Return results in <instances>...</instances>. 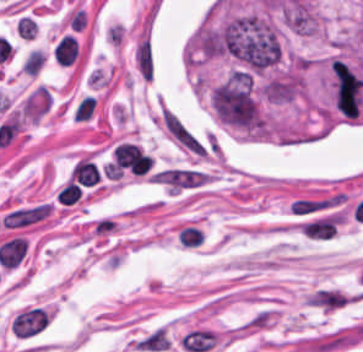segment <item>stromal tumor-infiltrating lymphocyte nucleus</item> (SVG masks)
Listing matches in <instances>:
<instances>
[{"label": "stromal tumor-infiltrating lymphocyte nucleus", "mask_w": 363, "mask_h": 352, "mask_svg": "<svg viewBox=\"0 0 363 352\" xmlns=\"http://www.w3.org/2000/svg\"><path fill=\"white\" fill-rule=\"evenodd\" d=\"M78 53L77 40L71 34H64L56 43L53 50L54 60L59 65H70Z\"/></svg>", "instance_id": "stromal-tumor-infiltrating-lymphocyte-nucleus-1"}, {"label": "stromal tumor-infiltrating lymphocyte nucleus", "mask_w": 363, "mask_h": 352, "mask_svg": "<svg viewBox=\"0 0 363 352\" xmlns=\"http://www.w3.org/2000/svg\"><path fill=\"white\" fill-rule=\"evenodd\" d=\"M72 179L82 186H92L99 181V171L92 161L81 159L70 174Z\"/></svg>", "instance_id": "stromal-tumor-infiltrating-lymphocyte-nucleus-2"}, {"label": "stromal tumor-infiltrating lymphocyte nucleus", "mask_w": 363, "mask_h": 352, "mask_svg": "<svg viewBox=\"0 0 363 352\" xmlns=\"http://www.w3.org/2000/svg\"><path fill=\"white\" fill-rule=\"evenodd\" d=\"M46 56L37 49L30 51L22 62L21 68L26 74H36L45 62Z\"/></svg>", "instance_id": "stromal-tumor-infiltrating-lymphocyte-nucleus-4"}, {"label": "stromal tumor-infiltrating lymphocyte nucleus", "mask_w": 363, "mask_h": 352, "mask_svg": "<svg viewBox=\"0 0 363 352\" xmlns=\"http://www.w3.org/2000/svg\"><path fill=\"white\" fill-rule=\"evenodd\" d=\"M96 106V97L85 95L77 104L74 111V121L88 118Z\"/></svg>", "instance_id": "stromal-tumor-infiltrating-lymphocyte-nucleus-6"}, {"label": "stromal tumor-infiltrating lymphocyte nucleus", "mask_w": 363, "mask_h": 352, "mask_svg": "<svg viewBox=\"0 0 363 352\" xmlns=\"http://www.w3.org/2000/svg\"><path fill=\"white\" fill-rule=\"evenodd\" d=\"M177 238L183 247H196L202 239V231L191 225H184L177 231Z\"/></svg>", "instance_id": "stromal-tumor-infiltrating-lymphocyte-nucleus-3"}, {"label": "stromal tumor-infiltrating lymphocyte nucleus", "mask_w": 363, "mask_h": 352, "mask_svg": "<svg viewBox=\"0 0 363 352\" xmlns=\"http://www.w3.org/2000/svg\"><path fill=\"white\" fill-rule=\"evenodd\" d=\"M81 196V190L79 187L72 181L68 180L59 190L57 195V202L59 204H72Z\"/></svg>", "instance_id": "stromal-tumor-infiltrating-lymphocyte-nucleus-5"}]
</instances>
